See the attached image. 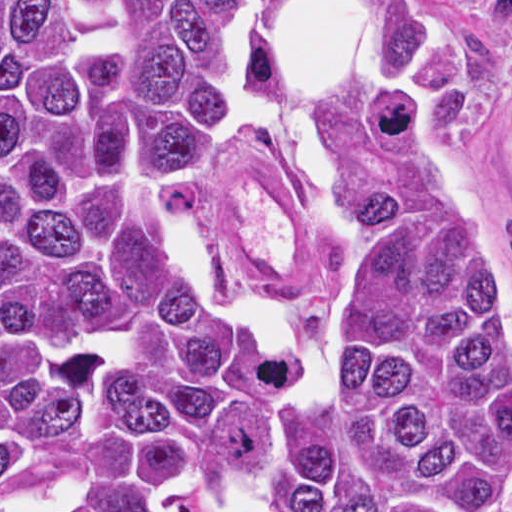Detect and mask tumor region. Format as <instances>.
I'll use <instances>...</instances> for the list:
<instances>
[{
	"mask_svg": "<svg viewBox=\"0 0 512 512\" xmlns=\"http://www.w3.org/2000/svg\"><path fill=\"white\" fill-rule=\"evenodd\" d=\"M282 2L0 0V512H512L509 268L414 0L372 4L400 76L349 94L330 328L195 260L219 59L267 80Z\"/></svg>",
	"mask_w": 512,
	"mask_h": 512,
	"instance_id": "e687c5a6",
	"label": "tumor region"
}]
</instances>
